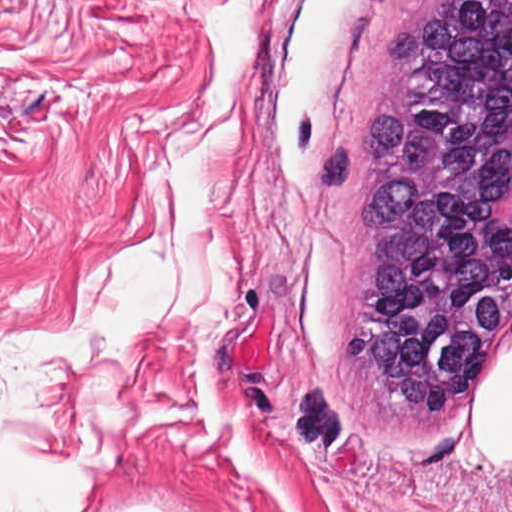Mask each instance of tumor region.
<instances>
[{
	"label": "tumor region",
	"mask_w": 512,
	"mask_h": 512,
	"mask_svg": "<svg viewBox=\"0 0 512 512\" xmlns=\"http://www.w3.org/2000/svg\"><path fill=\"white\" fill-rule=\"evenodd\" d=\"M511 166L512 0H411L360 140L329 149L310 193L366 186L339 348L391 450L471 387L512 324Z\"/></svg>",
	"instance_id": "e687c5a6"
}]
</instances>
